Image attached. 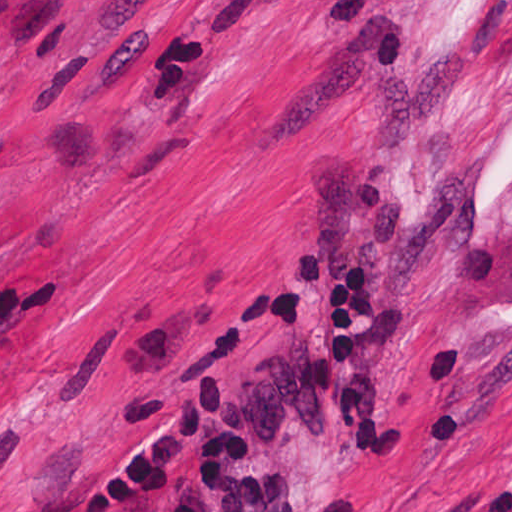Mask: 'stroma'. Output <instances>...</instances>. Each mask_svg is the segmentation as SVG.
I'll list each match as a JSON object with an SVG mask.
<instances>
[{"mask_svg":"<svg viewBox=\"0 0 512 512\" xmlns=\"http://www.w3.org/2000/svg\"><path fill=\"white\" fill-rule=\"evenodd\" d=\"M402 444L308 388L330 268ZM512 512V0H0V509Z\"/></svg>","mask_w":512,"mask_h":512,"instance_id":"stroma-1","label":"stroma"}]
</instances>
